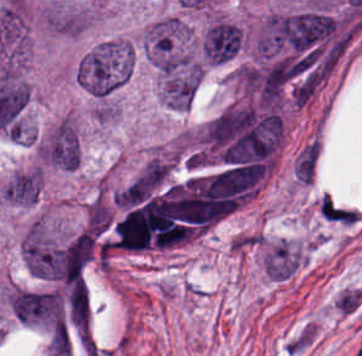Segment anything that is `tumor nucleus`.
Masks as SVG:
<instances>
[{
  "mask_svg": "<svg viewBox=\"0 0 362 356\" xmlns=\"http://www.w3.org/2000/svg\"><path fill=\"white\" fill-rule=\"evenodd\" d=\"M133 69V49L127 40H108L79 62V85L97 98H106L129 78Z\"/></svg>",
  "mask_w": 362,
  "mask_h": 356,
  "instance_id": "1",
  "label": "tumor nucleus"
},
{
  "mask_svg": "<svg viewBox=\"0 0 362 356\" xmlns=\"http://www.w3.org/2000/svg\"><path fill=\"white\" fill-rule=\"evenodd\" d=\"M145 48L161 75L172 76L194 62L190 34L174 16H167L145 29Z\"/></svg>",
  "mask_w": 362,
  "mask_h": 356,
  "instance_id": "2",
  "label": "tumor nucleus"
},
{
  "mask_svg": "<svg viewBox=\"0 0 362 356\" xmlns=\"http://www.w3.org/2000/svg\"><path fill=\"white\" fill-rule=\"evenodd\" d=\"M21 251L27 268L36 278L57 285L63 280L65 247L41 215L26 228Z\"/></svg>",
  "mask_w": 362,
  "mask_h": 356,
  "instance_id": "3",
  "label": "tumor nucleus"
},
{
  "mask_svg": "<svg viewBox=\"0 0 362 356\" xmlns=\"http://www.w3.org/2000/svg\"><path fill=\"white\" fill-rule=\"evenodd\" d=\"M8 300L18 321L51 331L62 323L61 297L53 289L10 287Z\"/></svg>",
  "mask_w": 362,
  "mask_h": 356,
  "instance_id": "4",
  "label": "tumor nucleus"
},
{
  "mask_svg": "<svg viewBox=\"0 0 362 356\" xmlns=\"http://www.w3.org/2000/svg\"><path fill=\"white\" fill-rule=\"evenodd\" d=\"M36 158L39 164L73 170L81 161V145L73 120L63 117L38 141Z\"/></svg>",
  "mask_w": 362,
  "mask_h": 356,
  "instance_id": "5",
  "label": "tumor nucleus"
},
{
  "mask_svg": "<svg viewBox=\"0 0 362 356\" xmlns=\"http://www.w3.org/2000/svg\"><path fill=\"white\" fill-rule=\"evenodd\" d=\"M242 30L233 23L217 20L203 39V53L211 63H220L234 55L241 45Z\"/></svg>",
  "mask_w": 362,
  "mask_h": 356,
  "instance_id": "6",
  "label": "tumor nucleus"
},
{
  "mask_svg": "<svg viewBox=\"0 0 362 356\" xmlns=\"http://www.w3.org/2000/svg\"><path fill=\"white\" fill-rule=\"evenodd\" d=\"M42 191V171L36 166L16 171L3 185L1 200L18 206L36 203Z\"/></svg>",
  "mask_w": 362,
  "mask_h": 356,
  "instance_id": "7",
  "label": "tumor nucleus"
}]
</instances>
